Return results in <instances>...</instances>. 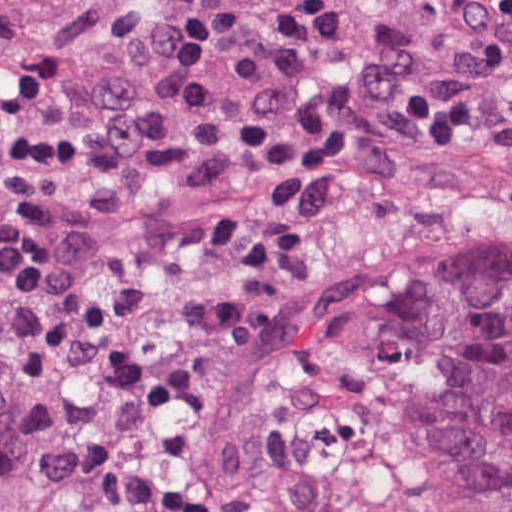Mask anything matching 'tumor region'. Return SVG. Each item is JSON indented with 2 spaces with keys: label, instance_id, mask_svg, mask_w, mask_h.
Instances as JSON below:
<instances>
[{
  "label": "tumor region",
  "instance_id": "1",
  "mask_svg": "<svg viewBox=\"0 0 512 512\" xmlns=\"http://www.w3.org/2000/svg\"><path fill=\"white\" fill-rule=\"evenodd\" d=\"M0 512H512V267L346 355L303 409L156 486L0 488Z\"/></svg>",
  "mask_w": 512,
  "mask_h": 512
}]
</instances>
